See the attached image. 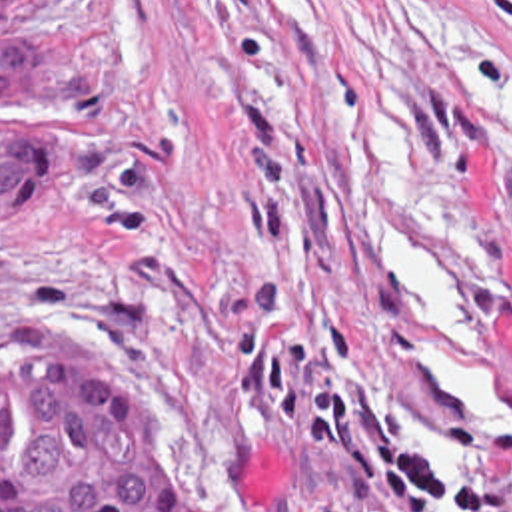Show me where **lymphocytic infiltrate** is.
Returning a JSON list of instances; mask_svg holds the SVG:
<instances>
[{"label":"lymphocytic infiltrate","instance_id":"1","mask_svg":"<svg viewBox=\"0 0 512 512\" xmlns=\"http://www.w3.org/2000/svg\"><path fill=\"white\" fill-rule=\"evenodd\" d=\"M249 324L233 334L249 368L237 396L273 408L293 450L321 454L335 466L347 512H419L461 508L501 512V486L475 476H441L419 440L385 428L335 374L317 366L355 360V336L341 324H323L317 344L267 336L277 308L273 276H251L245 286Z\"/></svg>","mask_w":512,"mask_h":512}]
</instances>
